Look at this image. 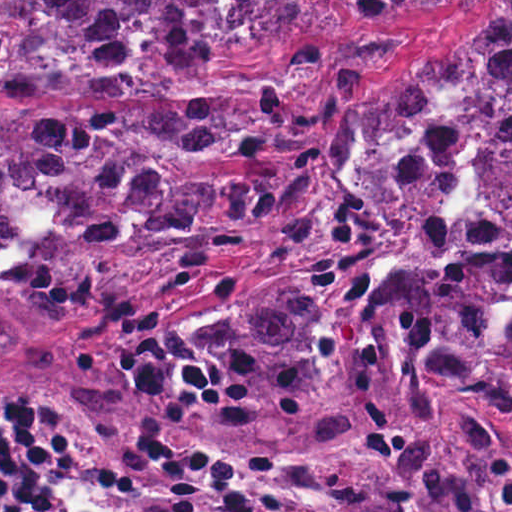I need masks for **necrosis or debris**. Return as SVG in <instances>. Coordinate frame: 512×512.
I'll list each match as a JSON object with an SVG mask.
<instances>
[{"label": "necrosis or debris", "instance_id": "obj_1", "mask_svg": "<svg viewBox=\"0 0 512 512\" xmlns=\"http://www.w3.org/2000/svg\"><path fill=\"white\" fill-rule=\"evenodd\" d=\"M61 0H0V70L19 66L45 39Z\"/></svg>", "mask_w": 512, "mask_h": 512}]
</instances>
